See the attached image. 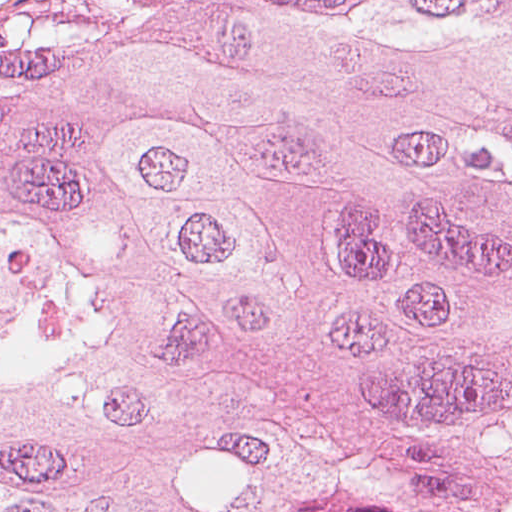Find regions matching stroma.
<instances>
[{"instance_id":"35a3bbf8","label":"stroma","mask_w":512,"mask_h":512,"mask_svg":"<svg viewBox=\"0 0 512 512\" xmlns=\"http://www.w3.org/2000/svg\"><path fill=\"white\" fill-rule=\"evenodd\" d=\"M46 0H0V20Z\"/></svg>"}]
</instances>
